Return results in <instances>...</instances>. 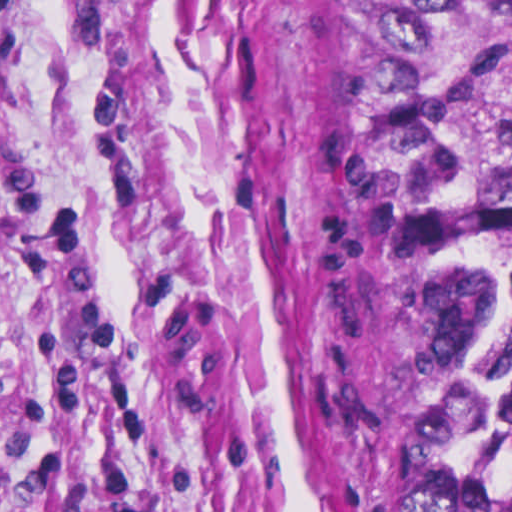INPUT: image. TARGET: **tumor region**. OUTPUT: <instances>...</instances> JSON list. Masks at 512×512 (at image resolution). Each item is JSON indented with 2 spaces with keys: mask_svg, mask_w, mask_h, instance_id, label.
<instances>
[{
  "mask_svg": "<svg viewBox=\"0 0 512 512\" xmlns=\"http://www.w3.org/2000/svg\"><path fill=\"white\" fill-rule=\"evenodd\" d=\"M369 279L397 512H512V0H379Z\"/></svg>",
  "mask_w": 512,
  "mask_h": 512,
  "instance_id": "1",
  "label": "tumor region"
}]
</instances>
